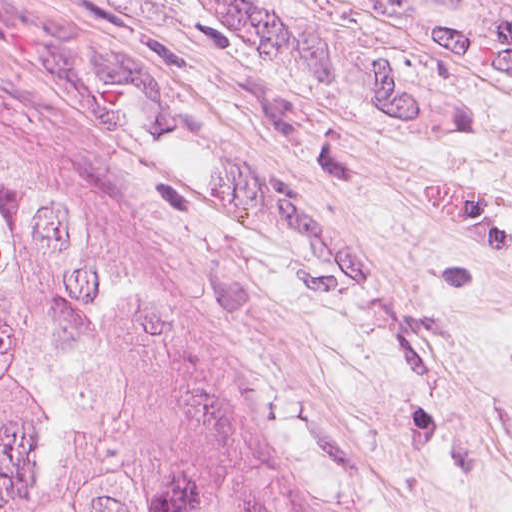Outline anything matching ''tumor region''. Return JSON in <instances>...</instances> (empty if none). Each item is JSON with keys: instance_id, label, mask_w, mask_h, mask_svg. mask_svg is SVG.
Instances as JSON below:
<instances>
[{"instance_id": "tumor-region-1", "label": "tumor region", "mask_w": 512, "mask_h": 512, "mask_svg": "<svg viewBox=\"0 0 512 512\" xmlns=\"http://www.w3.org/2000/svg\"><path fill=\"white\" fill-rule=\"evenodd\" d=\"M0 512H263L129 257L1 134Z\"/></svg>"}]
</instances>
